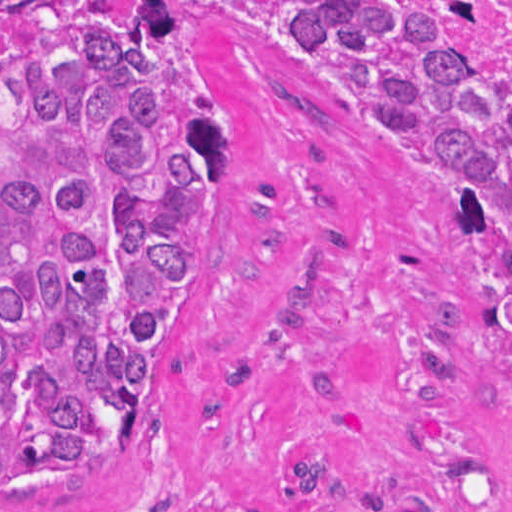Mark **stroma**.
<instances>
[{
  "instance_id": "35a3bbf8",
  "label": "stroma",
  "mask_w": 512,
  "mask_h": 512,
  "mask_svg": "<svg viewBox=\"0 0 512 512\" xmlns=\"http://www.w3.org/2000/svg\"><path fill=\"white\" fill-rule=\"evenodd\" d=\"M186 1L224 81L198 273L121 462L0 512H512V380L486 284L417 158L325 100L271 40L278 1Z\"/></svg>"
}]
</instances>
